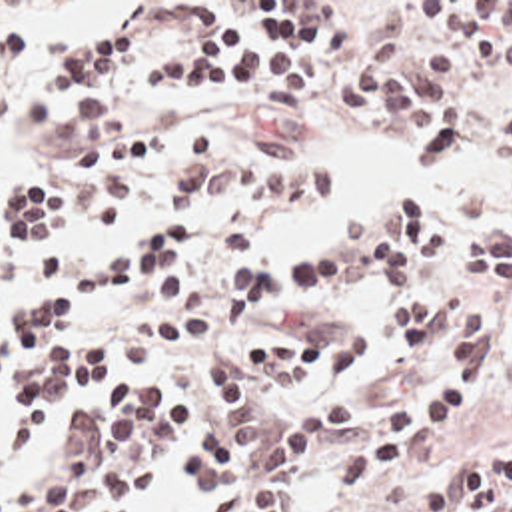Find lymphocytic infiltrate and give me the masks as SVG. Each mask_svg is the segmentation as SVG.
Instances as JSON below:
<instances>
[{"label":"lymphocytic infiltrate","instance_id":"f902f5d3","mask_svg":"<svg viewBox=\"0 0 512 512\" xmlns=\"http://www.w3.org/2000/svg\"><path fill=\"white\" fill-rule=\"evenodd\" d=\"M325 2H253L243 24L225 2H195L181 12L199 50L145 70V98L177 84L195 98L247 94L259 118H289L315 80L317 56L345 50L347 26ZM413 22L459 40L423 44L405 32L375 40L347 72L341 94L351 108L407 114L423 164H449L479 150L483 160L512 166V2H411ZM58 54L26 94L34 130L56 124L72 138L66 198L78 216L113 228L123 222L135 182L161 176L169 212L221 210L219 248H243L275 204H317L333 196V170L291 140L251 138L231 158L221 140L193 132L163 138L141 130L102 98L103 76L129 72L147 56L143 28L127 22L105 34L82 36L58 26L12 22L0 28V62L24 60L46 46ZM64 208V190L50 178H16L0 186V278L22 288L68 286L70 292H111L149 280L187 248L179 220L141 228L102 262L70 272V254L50 232ZM363 268L387 286V329L397 341L395 365L355 395L293 405L263 415L271 391L289 383H337L367 359L369 337L355 323L325 317L301 333L265 343L203 353V373L227 411V425L195 431L167 409V395L131 383L103 405L80 411L68 431V451L40 475L0 491V512H141L135 497L161 481L183 451L189 491L209 512H281L285 481L307 459L331 447L391 383L445 371L419 399L395 403L387 433L323 463L333 495L397 465L417 427L451 419L475 401L465 371L485 367L483 313L477 288L512 292L511 208L469 234L459 284L445 296L411 292L415 274L431 266L451 234L417 188L405 186L339 230ZM347 280L343 250H323L291 268L235 258L219 270V325H253L271 290H313ZM209 333L197 308L153 313L125 329L105 327L94 347H78L74 312L56 292L16 312H0V433L16 405V429L38 431L66 401L96 391L123 371H147L175 349ZM512 361V312L499 335ZM411 505L419 512H512V447H485L415 479Z\"/></svg>","mask_w":512,"mask_h":512}]
</instances>
